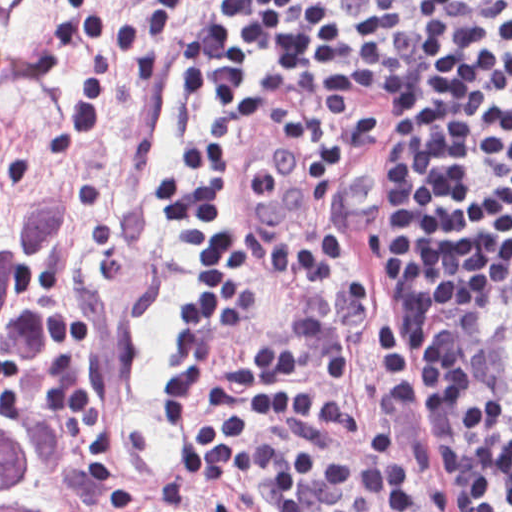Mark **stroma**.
Wrapping results in <instances>:
<instances>
[{
  "mask_svg": "<svg viewBox=\"0 0 512 512\" xmlns=\"http://www.w3.org/2000/svg\"><path fill=\"white\" fill-rule=\"evenodd\" d=\"M239 0L197 13L171 48L163 82L114 99L100 137L71 159L49 139L69 114L83 59L58 71L45 35L60 7L0 0V207L42 208L70 186L83 195L75 226L36 279L60 398L104 484L70 497L55 482L54 512H165L173 447L158 409V372L174 351L176 305L188 291L150 187L197 128L181 57L183 33L220 20ZM120 0H102L101 26ZM233 194L244 204L258 259L254 297L206 377L254 408L264 438L351 447L375 430L399 447L413 512H441L426 425L394 308L406 319V104L403 88L357 64L290 67L230 104ZM512 257L452 317L491 295ZM451 317V318H452ZM0 418L39 445L10 367L0 362ZM270 512L252 476L206 496ZM253 510V512H257Z\"/></svg>",
  "mask_w": 512,
  "mask_h": 512,
  "instance_id": "stroma-1",
  "label": "stroma"
}]
</instances>
